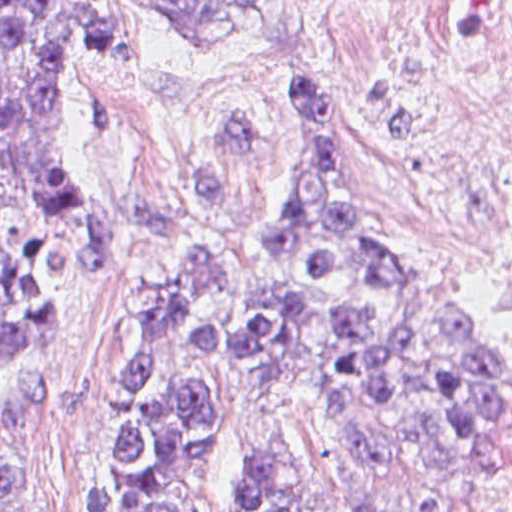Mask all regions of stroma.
<instances>
[{"mask_svg":"<svg viewBox=\"0 0 512 512\" xmlns=\"http://www.w3.org/2000/svg\"><path fill=\"white\" fill-rule=\"evenodd\" d=\"M380 0H306L258 48L186 36L161 0H100L96 37L57 95L76 177L116 266L73 280L57 322L0 363V445L33 466V512H102L90 477L134 309L159 266L201 241L248 260L252 215L296 92L397 262L512 352L490 284L446 239L387 206L362 128V44Z\"/></svg>","mask_w":512,"mask_h":512,"instance_id":"35a3bbf8","label":"stroma"}]
</instances>
